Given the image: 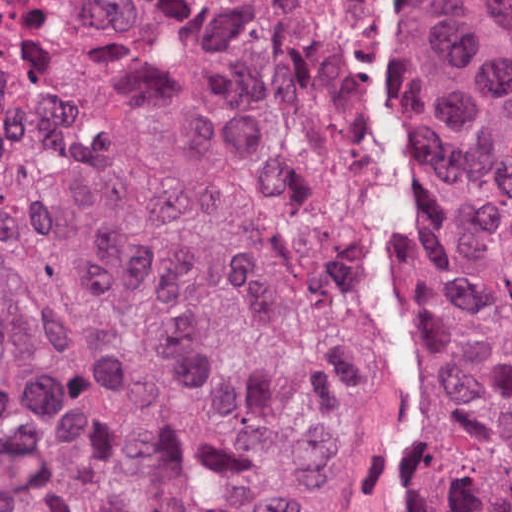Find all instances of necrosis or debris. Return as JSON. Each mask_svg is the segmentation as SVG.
<instances>
[{
	"mask_svg": "<svg viewBox=\"0 0 512 512\" xmlns=\"http://www.w3.org/2000/svg\"><path fill=\"white\" fill-rule=\"evenodd\" d=\"M357 9H384L380 0H350ZM500 46L512 49V0H465Z\"/></svg>",
	"mask_w": 512,
	"mask_h": 512,
	"instance_id": "necrosis-or-debris-1",
	"label": "necrosis or debris"
}]
</instances>
